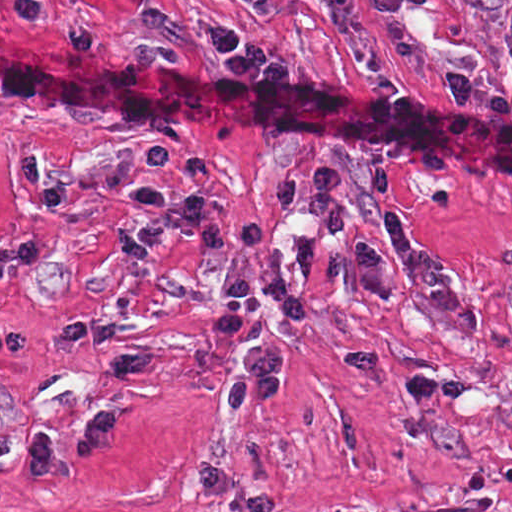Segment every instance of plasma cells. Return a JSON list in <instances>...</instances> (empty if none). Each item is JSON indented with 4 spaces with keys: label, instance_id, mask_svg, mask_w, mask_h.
I'll use <instances>...</instances> for the list:
<instances>
[{
    "label": "plasma cells",
    "instance_id": "plasma-cells-1",
    "mask_svg": "<svg viewBox=\"0 0 512 512\" xmlns=\"http://www.w3.org/2000/svg\"><path fill=\"white\" fill-rule=\"evenodd\" d=\"M314 1L357 63L365 67L381 65L384 56L378 49L382 45L392 57L426 75L461 105L473 104V81L431 59L405 24V13L426 0H372L379 16L380 32L376 35L362 27L357 0ZM127 194L130 202L126 208L137 215L134 235L145 250L157 247L166 229H175L186 243L212 256L226 254L239 245L248 249L223 269L225 294L208 323L219 337L250 338L246 353L226 370L229 420L280 403L286 347L279 332L265 321L263 300L271 298L296 320H309L320 312L309 291L318 276L330 275L341 286L360 287L378 298L395 301L399 294L391 276L400 272L414 282L438 316L460 336L473 338L486 331L485 319L445 252L423 241L397 205L388 170L376 173V198L389 237L399 249L396 257L388 258L373 244L363 243L326 259L314 240L306 236L298 242L294 268L287 274L282 267L280 243L259 217L251 216L240 228L229 231L211 212L201 192L178 198L162 189L137 188Z\"/></svg>",
    "mask_w": 512,
    "mask_h": 512
}]
</instances>
